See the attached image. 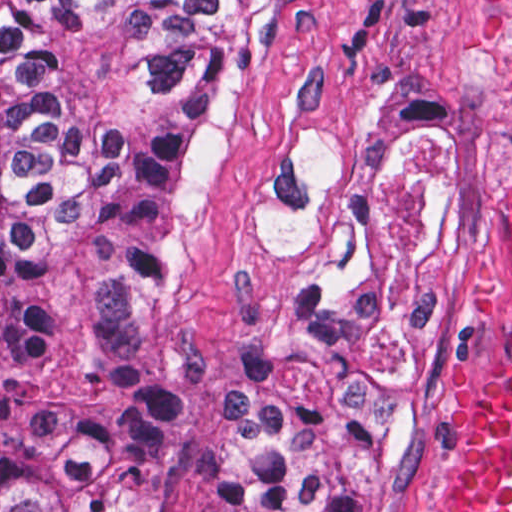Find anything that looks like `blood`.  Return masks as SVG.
Listing matches in <instances>:
<instances>
[{
	"mask_svg": "<svg viewBox=\"0 0 512 512\" xmlns=\"http://www.w3.org/2000/svg\"><path fill=\"white\" fill-rule=\"evenodd\" d=\"M512 121V42L500 60ZM435 512H512V203L493 290L475 319V389L443 464Z\"/></svg>",
	"mask_w": 512,
	"mask_h": 512,
	"instance_id": "1a1defca",
	"label": "blood"
}]
</instances>
